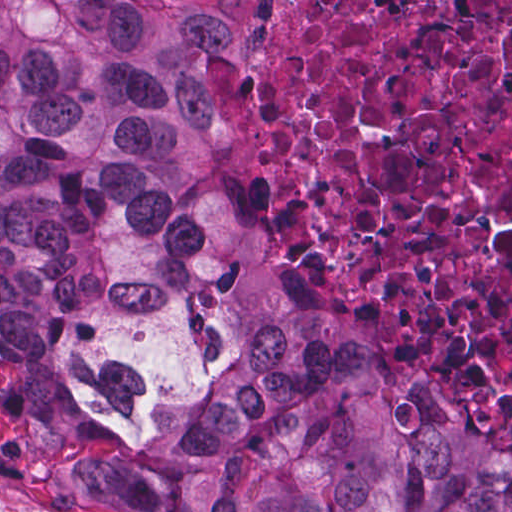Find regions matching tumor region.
<instances>
[{
    "mask_svg": "<svg viewBox=\"0 0 512 512\" xmlns=\"http://www.w3.org/2000/svg\"><path fill=\"white\" fill-rule=\"evenodd\" d=\"M247 43L248 0H0V463L112 512H512V442L207 169L199 60Z\"/></svg>",
    "mask_w": 512,
    "mask_h": 512,
    "instance_id": "obj_1",
    "label": "tumor region"
}]
</instances>
